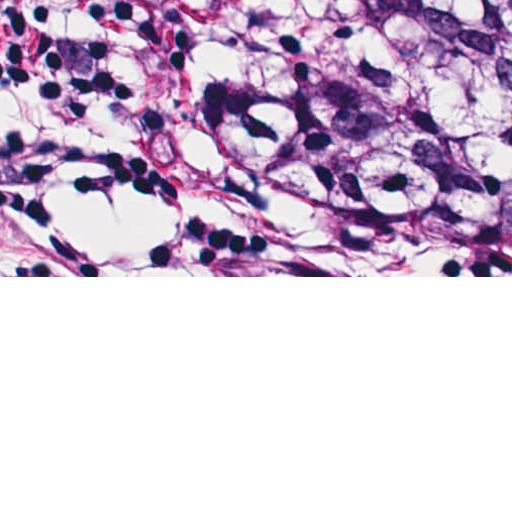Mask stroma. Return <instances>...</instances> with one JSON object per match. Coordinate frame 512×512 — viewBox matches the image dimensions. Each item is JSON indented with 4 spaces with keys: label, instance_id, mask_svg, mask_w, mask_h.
<instances>
[{
    "label": "stroma",
    "instance_id": "1",
    "mask_svg": "<svg viewBox=\"0 0 512 512\" xmlns=\"http://www.w3.org/2000/svg\"><path fill=\"white\" fill-rule=\"evenodd\" d=\"M101 3L153 127L204 198L239 276L0 277H512V244L378 253L311 243L266 186L211 142L205 106L219 90L216 53L151 26L128 0Z\"/></svg>",
    "mask_w": 512,
    "mask_h": 512
}]
</instances>
